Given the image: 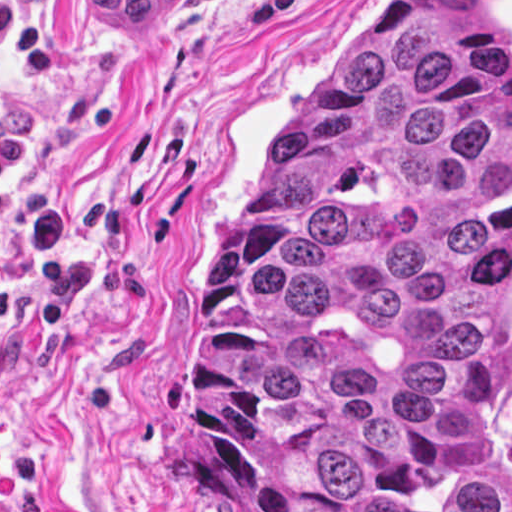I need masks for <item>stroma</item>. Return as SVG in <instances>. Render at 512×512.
Listing matches in <instances>:
<instances>
[{
  "mask_svg": "<svg viewBox=\"0 0 512 512\" xmlns=\"http://www.w3.org/2000/svg\"><path fill=\"white\" fill-rule=\"evenodd\" d=\"M45 30L0 116L31 157L0 222V512H223L192 467L185 317L273 133L350 20L382 0H173L140 28L7 0ZM512 63V0H487Z\"/></svg>",
  "mask_w": 512,
  "mask_h": 512,
  "instance_id": "35a3bbf8",
  "label": "stroma"
}]
</instances>
